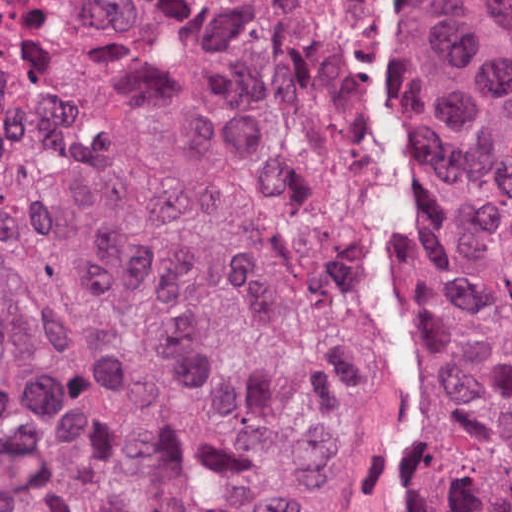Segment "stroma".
Wrapping results in <instances>:
<instances>
[{
  "label": "stroma",
  "instance_id": "1",
  "mask_svg": "<svg viewBox=\"0 0 512 512\" xmlns=\"http://www.w3.org/2000/svg\"><path fill=\"white\" fill-rule=\"evenodd\" d=\"M384 9H357L363 45V75L367 92V160L382 118L407 100L400 53L393 22L392 0H380ZM475 26L488 46L512 75V49L499 45L488 28L465 0H450ZM419 203V166L415 152V218ZM427 278L415 260L408 288V332L415 360L419 325V297ZM421 435L452 512H470L455 483L450 459L439 446L421 411Z\"/></svg>",
  "mask_w": 512,
  "mask_h": 512
}]
</instances>
